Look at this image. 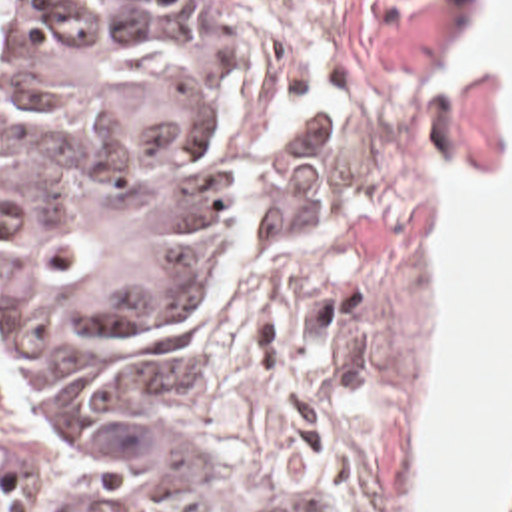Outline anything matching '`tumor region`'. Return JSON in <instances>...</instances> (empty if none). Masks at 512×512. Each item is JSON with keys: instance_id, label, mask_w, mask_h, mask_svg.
<instances>
[{"instance_id": "tumor-region-1", "label": "tumor region", "mask_w": 512, "mask_h": 512, "mask_svg": "<svg viewBox=\"0 0 512 512\" xmlns=\"http://www.w3.org/2000/svg\"><path fill=\"white\" fill-rule=\"evenodd\" d=\"M269 139L211 0H9L0 309L75 512H237L165 399V343L253 261ZM494 512H512V441Z\"/></svg>"}]
</instances>
